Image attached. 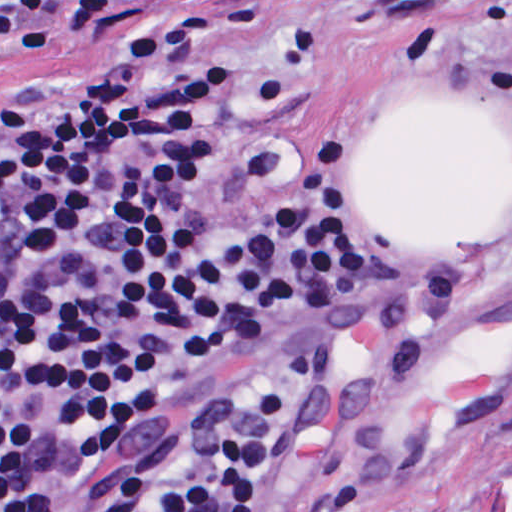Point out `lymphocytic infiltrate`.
I'll return each mask as SVG.
<instances>
[{"label":"lymphocytic infiltrate","instance_id":"obj_1","mask_svg":"<svg viewBox=\"0 0 512 512\" xmlns=\"http://www.w3.org/2000/svg\"><path fill=\"white\" fill-rule=\"evenodd\" d=\"M104 0H0V64L85 28ZM242 25L185 15L87 76L0 110V512H244L279 439L290 372L399 313L379 162L299 136L190 200L219 130ZM378 290L329 343L179 443L90 485L44 456L46 415L117 448L169 391L291 310Z\"/></svg>","mask_w":512,"mask_h":512}]
</instances>
